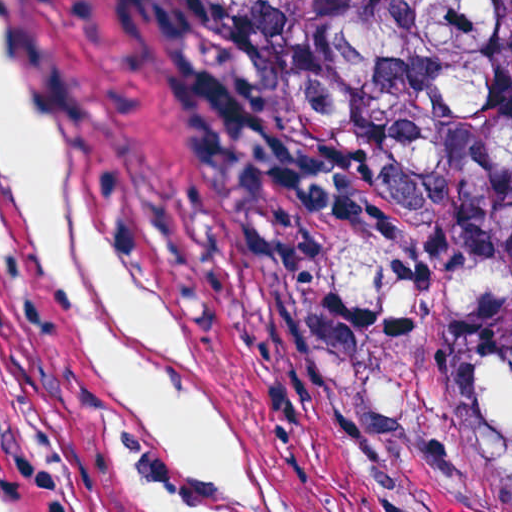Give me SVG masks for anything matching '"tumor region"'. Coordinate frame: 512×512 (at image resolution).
Returning a JSON list of instances; mask_svg holds the SVG:
<instances>
[{"label":"tumor region","instance_id":"tumor-region-1","mask_svg":"<svg viewBox=\"0 0 512 512\" xmlns=\"http://www.w3.org/2000/svg\"><path fill=\"white\" fill-rule=\"evenodd\" d=\"M372 512H512V0H157Z\"/></svg>","mask_w":512,"mask_h":512}]
</instances>
